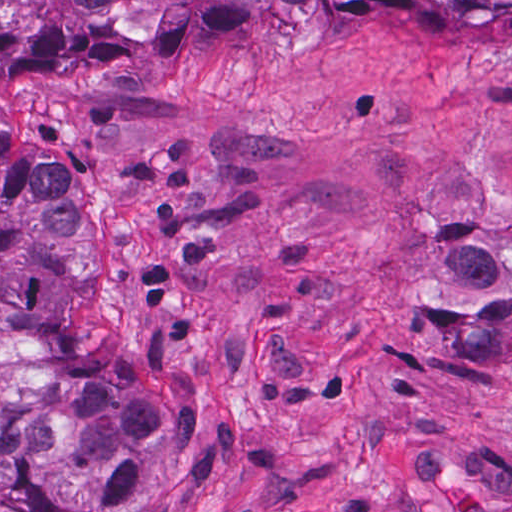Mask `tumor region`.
<instances>
[{"mask_svg": "<svg viewBox=\"0 0 512 512\" xmlns=\"http://www.w3.org/2000/svg\"><path fill=\"white\" fill-rule=\"evenodd\" d=\"M512 0H0V71L53 42L155 47L289 4ZM105 274L68 164L0 119V485L22 512H179L218 460L195 381L144 365L95 326ZM479 336L512 343V314Z\"/></svg>", "mask_w": 512, "mask_h": 512, "instance_id": "e687c5a6", "label": "tumor region"}]
</instances>
